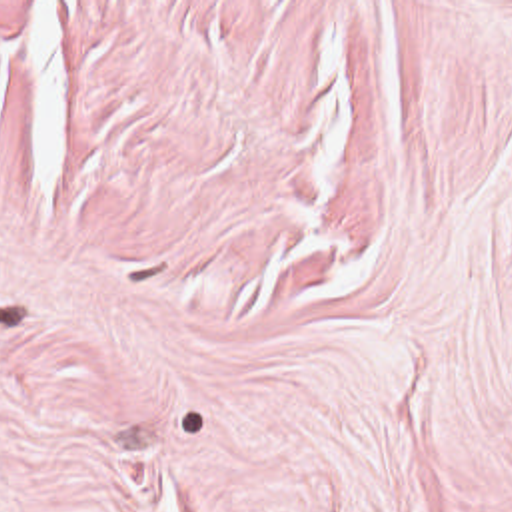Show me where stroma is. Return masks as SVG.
Returning a JSON list of instances; mask_svg holds the SVG:
<instances>
[{
	"instance_id": "obj_1",
	"label": "stroma",
	"mask_w": 512,
	"mask_h": 512,
	"mask_svg": "<svg viewBox=\"0 0 512 512\" xmlns=\"http://www.w3.org/2000/svg\"><path fill=\"white\" fill-rule=\"evenodd\" d=\"M0 512H512V0H0Z\"/></svg>"
}]
</instances>
